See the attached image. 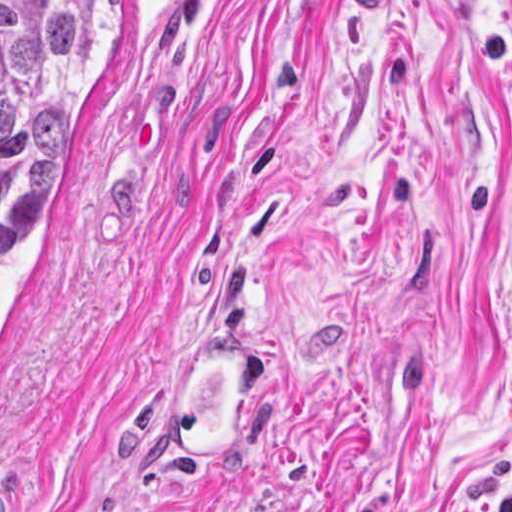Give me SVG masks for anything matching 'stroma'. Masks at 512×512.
Segmentation results:
<instances>
[{
  "mask_svg": "<svg viewBox=\"0 0 512 512\" xmlns=\"http://www.w3.org/2000/svg\"><path fill=\"white\" fill-rule=\"evenodd\" d=\"M103 1L0 242L12 512H512V0ZM255 343L207 470L158 429Z\"/></svg>",
  "mask_w": 512,
  "mask_h": 512,
  "instance_id": "1",
  "label": "stroma"
}]
</instances>
